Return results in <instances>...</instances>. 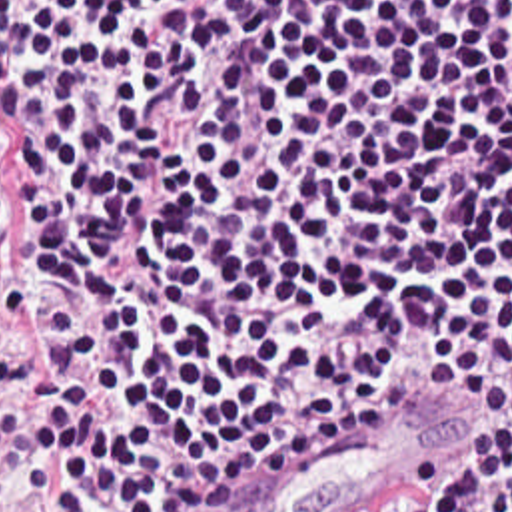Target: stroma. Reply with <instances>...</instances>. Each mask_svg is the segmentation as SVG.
Returning a JSON list of instances; mask_svg holds the SVG:
<instances>
[{
	"label": "stroma",
	"instance_id": "1",
	"mask_svg": "<svg viewBox=\"0 0 512 512\" xmlns=\"http://www.w3.org/2000/svg\"><path fill=\"white\" fill-rule=\"evenodd\" d=\"M0 512H47L41 500L15 494H0Z\"/></svg>",
	"mask_w": 512,
	"mask_h": 512
}]
</instances>
